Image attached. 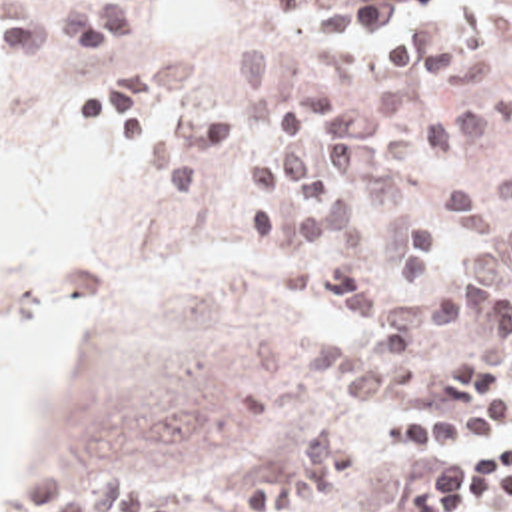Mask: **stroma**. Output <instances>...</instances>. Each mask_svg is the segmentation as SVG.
Here are the masks:
<instances>
[{"instance_id":"stroma-1","label":"stroma","mask_w":512,"mask_h":512,"mask_svg":"<svg viewBox=\"0 0 512 512\" xmlns=\"http://www.w3.org/2000/svg\"><path fill=\"white\" fill-rule=\"evenodd\" d=\"M100 2L0 0V16H60ZM126 2L134 4V41L116 55L70 63L60 51L0 61V151H18L96 105L108 185V255L86 279L94 287V327L44 387L40 461L28 481L0 487V512L18 511L50 471H74L88 487L118 463L138 471L146 491L174 499L176 512H248L240 509L242 491L277 475L315 433L331 427L363 435V469L349 487L299 512H401L403 491L425 455H395L377 431L397 417H449L455 409L443 395V373L465 357L512 373L505 339L512 279L423 349L413 373L365 409H347L337 383L307 379L309 341L363 331L283 285L279 235L260 247L240 225L242 207L258 195L244 157L275 151L283 127L267 117L265 95L244 85L232 55L263 47L279 69L329 81L337 113L363 111L377 87L399 83L411 89L413 107L393 123V135L413 131L433 113L491 109L493 135L405 169L423 195H441L512 175V8L451 0L449 10L403 20L405 29L455 20L461 41L469 33L463 10L477 6L483 28L509 43L511 67L473 85H435L391 67L373 35H343L339 47L321 49V12L283 18L271 0ZM164 55L188 59V103L228 109L238 119V149L214 169L198 199L154 189L104 97L108 73ZM58 287L0 285V323L44 309ZM461 511L512 512V499Z\"/></svg>"}]
</instances>
